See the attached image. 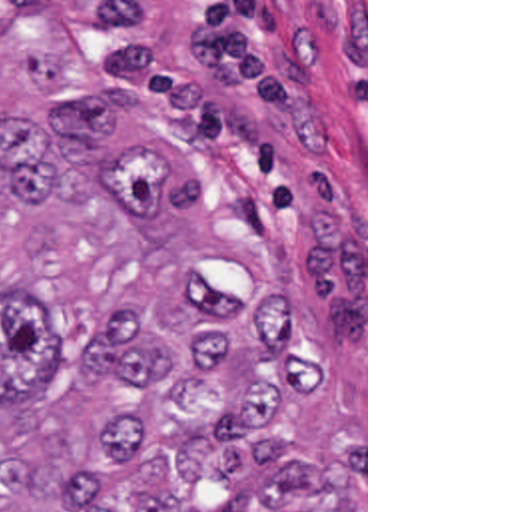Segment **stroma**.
Returning a JSON list of instances; mask_svg holds the SVG:
<instances>
[{
	"label": "stroma",
	"instance_id": "obj_1",
	"mask_svg": "<svg viewBox=\"0 0 512 512\" xmlns=\"http://www.w3.org/2000/svg\"><path fill=\"white\" fill-rule=\"evenodd\" d=\"M71 38L200 178L208 222L288 258L362 361L368 512V0H0Z\"/></svg>",
	"mask_w": 512,
	"mask_h": 512
}]
</instances>
